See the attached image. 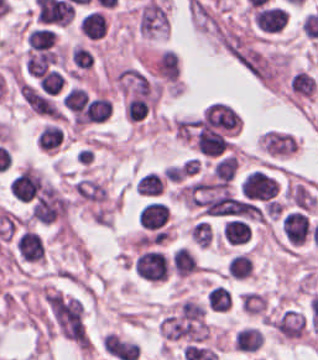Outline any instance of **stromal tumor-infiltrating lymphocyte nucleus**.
Segmentation results:
<instances>
[{"label":"stromal tumor-infiltrating lymphocyte nucleus","mask_w":318,"mask_h":360,"mask_svg":"<svg viewBox=\"0 0 318 360\" xmlns=\"http://www.w3.org/2000/svg\"><path fill=\"white\" fill-rule=\"evenodd\" d=\"M312 221L309 212L301 209H288L283 212L281 228L290 246H300L308 242Z\"/></svg>","instance_id":"bc302bb0"},{"label":"stromal tumor-infiltrating lymphocyte nucleus","mask_w":318,"mask_h":360,"mask_svg":"<svg viewBox=\"0 0 318 360\" xmlns=\"http://www.w3.org/2000/svg\"><path fill=\"white\" fill-rule=\"evenodd\" d=\"M278 183L264 171L252 170L243 180L242 196L269 201L274 197Z\"/></svg>","instance_id":"52c7bb5b"},{"label":"stromal tumor-infiltrating lymphocyte nucleus","mask_w":318,"mask_h":360,"mask_svg":"<svg viewBox=\"0 0 318 360\" xmlns=\"http://www.w3.org/2000/svg\"><path fill=\"white\" fill-rule=\"evenodd\" d=\"M16 258L28 263H37L45 255L43 240L38 232L22 228L14 239Z\"/></svg>","instance_id":"3290ff9b"},{"label":"stromal tumor-infiltrating lymphocyte nucleus","mask_w":318,"mask_h":360,"mask_svg":"<svg viewBox=\"0 0 318 360\" xmlns=\"http://www.w3.org/2000/svg\"><path fill=\"white\" fill-rule=\"evenodd\" d=\"M221 237L230 246H246L251 239V225L247 220L232 216L222 223Z\"/></svg>","instance_id":"abfb95fc"},{"label":"stromal tumor-infiltrating lymphocyte nucleus","mask_w":318,"mask_h":360,"mask_svg":"<svg viewBox=\"0 0 318 360\" xmlns=\"http://www.w3.org/2000/svg\"><path fill=\"white\" fill-rule=\"evenodd\" d=\"M262 146L269 154H289L296 144L294 135L282 129H268L262 135Z\"/></svg>","instance_id":"9ea309e8"},{"label":"stromal tumor-infiltrating lymphocyte nucleus","mask_w":318,"mask_h":360,"mask_svg":"<svg viewBox=\"0 0 318 360\" xmlns=\"http://www.w3.org/2000/svg\"><path fill=\"white\" fill-rule=\"evenodd\" d=\"M195 144L196 148L205 155L217 156L228 148L229 142L221 132L201 127Z\"/></svg>","instance_id":"f3e2335f"},{"label":"stromal tumor-infiltrating lymphocyte nucleus","mask_w":318,"mask_h":360,"mask_svg":"<svg viewBox=\"0 0 318 360\" xmlns=\"http://www.w3.org/2000/svg\"><path fill=\"white\" fill-rule=\"evenodd\" d=\"M169 213L164 201L153 200L139 209L137 222L140 227L156 229L165 223Z\"/></svg>","instance_id":"4f13568d"},{"label":"stromal tumor-infiltrating lymphocyte nucleus","mask_w":318,"mask_h":360,"mask_svg":"<svg viewBox=\"0 0 318 360\" xmlns=\"http://www.w3.org/2000/svg\"><path fill=\"white\" fill-rule=\"evenodd\" d=\"M36 140L42 150L57 151L65 140L63 127L55 121H47L37 132Z\"/></svg>","instance_id":"2a367800"},{"label":"stromal tumor-infiltrating lymphocyte nucleus","mask_w":318,"mask_h":360,"mask_svg":"<svg viewBox=\"0 0 318 360\" xmlns=\"http://www.w3.org/2000/svg\"><path fill=\"white\" fill-rule=\"evenodd\" d=\"M165 174L161 170H148L134 185L135 192L142 195H161Z\"/></svg>","instance_id":"4803ca6d"},{"label":"stromal tumor-infiltrating lymphocyte nucleus","mask_w":318,"mask_h":360,"mask_svg":"<svg viewBox=\"0 0 318 360\" xmlns=\"http://www.w3.org/2000/svg\"><path fill=\"white\" fill-rule=\"evenodd\" d=\"M232 302V292L222 284H215L205 295V304L212 311H227Z\"/></svg>","instance_id":"4245b91a"},{"label":"stromal tumor-infiltrating lymphocyte nucleus","mask_w":318,"mask_h":360,"mask_svg":"<svg viewBox=\"0 0 318 360\" xmlns=\"http://www.w3.org/2000/svg\"><path fill=\"white\" fill-rule=\"evenodd\" d=\"M233 344L236 350L255 351L262 345V335L258 329L246 328L236 335Z\"/></svg>","instance_id":"4c9ddf68"},{"label":"stromal tumor-infiltrating lymphocyte nucleus","mask_w":318,"mask_h":360,"mask_svg":"<svg viewBox=\"0 0 318 360\" xmlns=\"http://www.w3.org/2000/svg\"><path fill=\"white\" fill-rule=\"evenodd\" d=\"M237 166V159L234 155H227L222 158L212 171L220 186H227Z\"/></svg>","instance_id":"2761f720"},{"label":"stromal tumor-infiltrating lymphocyte nucleus","mask_w":318,"mask_h":360,"mask_svg":"<svg viewBox=\"0 0 318 360\" xmlns=\"http://www.w3.org/2000/svg\"><path fill=\"white\" fill-rule=\"evenodd\" d=\"M54 35L46 28H33L26 36L29 48L44 50L54 40Z\"/></svg>","instance_id":"3c572f05"},{"label":"stromal tumor-infiltrating lymphocyte nucleus","mask_w":318,"mask_h":360,"mask_svg":"<svg viewBox=\"0 0 318 360\" xmlns=\"http://www.w3.org/2000/svg\"><path fill=\"white\" fill-rule=\"evenodd\" d=\"M71 58L80 68H89L93 63L91 52L78 44L72 49Z\"/></svg>","instance_id":"42bb06b2"}]
</instances>
